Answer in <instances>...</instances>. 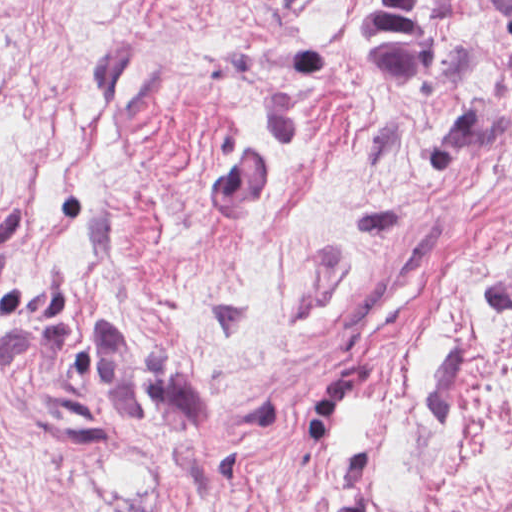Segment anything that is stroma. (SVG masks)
<instances>
[{"label": "stroma", "mask_w": 512, "mask_h": 512, "mask_svg": "<svg viewBox=\"0 0 512 512\" xmlns=\"http://www.w3.org/2000/svg\"><path fill=\"white\" fill-rule=\"evenodd\" d=\"M502 1L0 0V512H512Z\"/></svg>", "instance_id": "obj_1"}]
</instances>
